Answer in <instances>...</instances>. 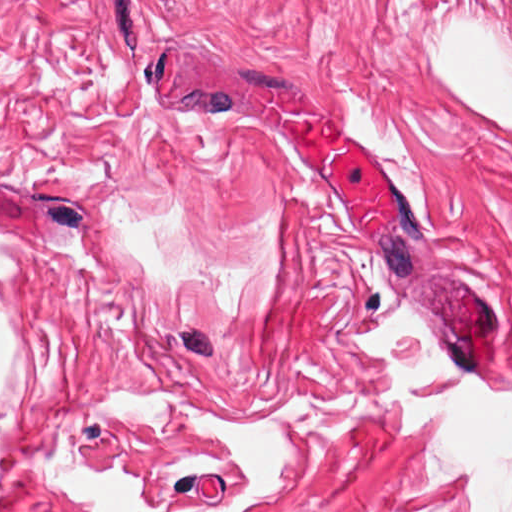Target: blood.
Segmentation results:
<instances>
[{
    "instance_id": "1a1defca",
    "label": "blood",
    "mask_w": 512,
    "mask_h": 512,
    "mask_svg": "<svg viewBox=\"0 0 512 512\" xmlns=\"http://www.w3.org/2000/svg\"><path fill=\"white\" fill-rule=\"evenodd\" d=\"M303 170L371 227L399 213L392 177L319 110H270ZM494 382L512 375L510 334L472 347Z\"/></svg>"
}]
</instances>
